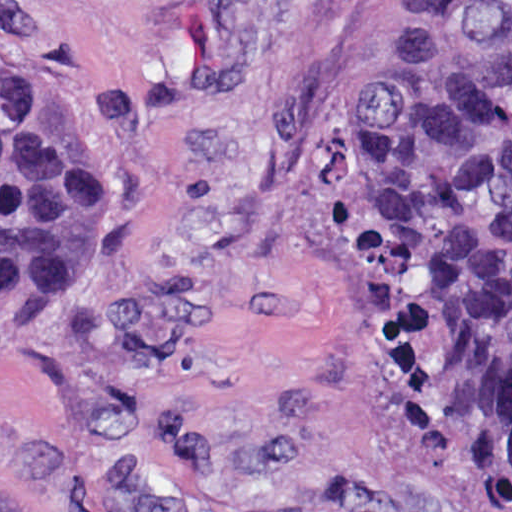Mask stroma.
I'll return each mask as SVG.
<instances>
[{
	"label": "stroma",
	"instance_id": "1",
	"mask_svg": "<svg viewBox=\"0 0 512 512\" xmlns=\"http://www.w3.org/2000/svg\"><path fill=\"white\" fill-rule=\"evenodd\" d=\"M1 66L94 157V250L1 297ZM0 512H512L377 388L352 0H0Z\"/></svg>",
	"mask_w": 512,
	"mask_h": 512
}]
</instances>
